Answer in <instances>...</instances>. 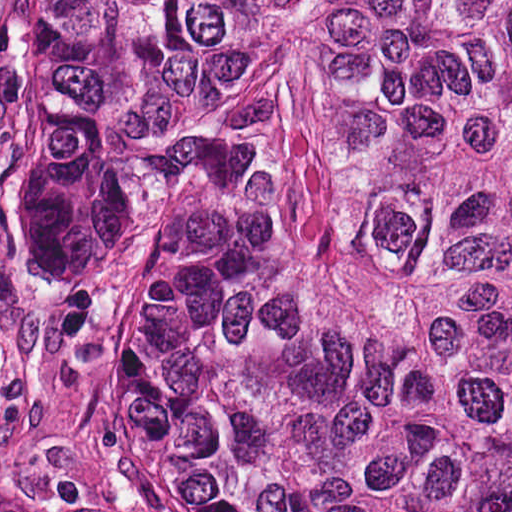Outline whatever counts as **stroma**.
<instances>
[{"mask_svg": "<svg viewBox=\"0 0 512 512\" xmlns=\"http://www.w3.org/2000/svg\"><path fill=\"white\" fill-rule=\"evenodd\" d=\"M65 379L58 315L28 225L20 0H0V498L51 512H188L145 482Z\"/></svg>", "mask_w": 512, "mask_h": 512, "instance_id": "obj_1", "label": "stroma"}]
</instances>
